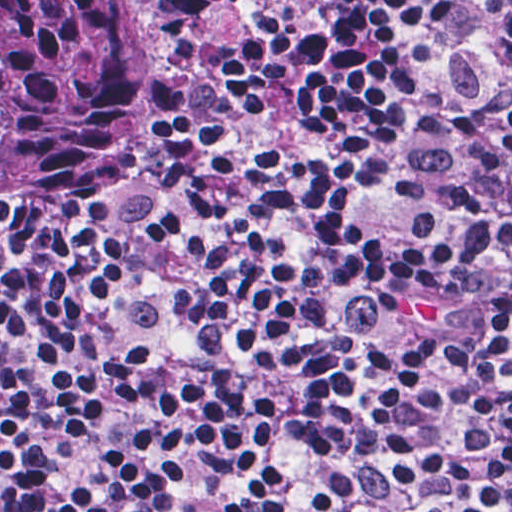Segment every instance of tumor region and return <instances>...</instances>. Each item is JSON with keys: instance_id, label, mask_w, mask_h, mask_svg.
Here are the masks:
<instances>
[{"instance_id": "obj_1", "label": "tumor region", "mask_w": 512, "mask_h": 512, "mask_svg": "<svg viewBox=\"0 0 512 512\" xmlns=\"http://www.w3.org/2000/svg\"><path fill=\"white\" fill-rule=\"evenodd\" d=\"M153 69L140 0H0V237L40 240L109 158Z\"/></svg>"}]
</instances>
